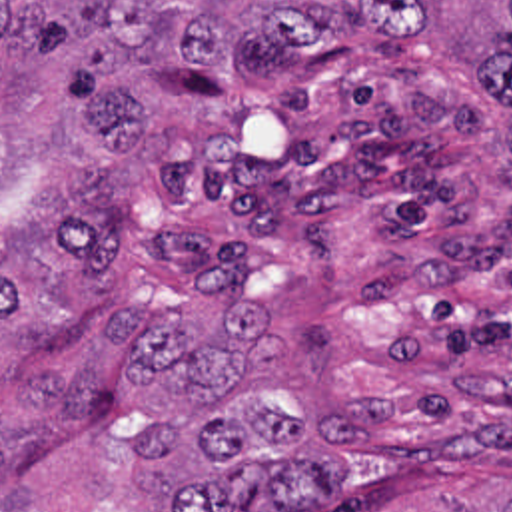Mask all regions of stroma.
<instances>
[{
  "label": "stroma",
  "instance_id": "1",
  "mask_svg": "<svg viewBox=\"0 0 512 512\" xmlns=\"http://www.w3.org/2000/svg\"><path fill=\"white\" fill-rule=\"evenodd\" d=\"M345 60L271 86L194 64L122 76L168 144L126 158L110 222L142 252L178 244L172 206L225 166L321 204V252L281 320L301 395L417 381L435 425L373 512H439L512 475V108L425 38L353 32ZM70 58L0 50V118L40 146L38 194L100 154L66 90Z\"/></svg>",
  "mask_w": 512,
  "mask_h": 512
}]
</instances>
